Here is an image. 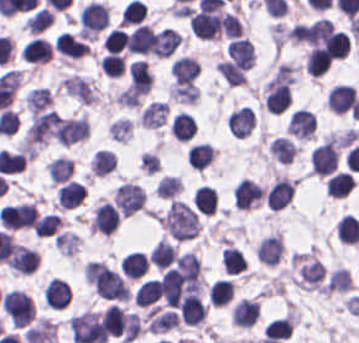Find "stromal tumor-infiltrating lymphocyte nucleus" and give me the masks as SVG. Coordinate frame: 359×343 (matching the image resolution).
I'll list each match as a JSON object with an SVG mask.
<instances>
[{"instance_id":"bc302bb0","label":"stromal tumor-infiltrating lymphocyte nucleus","mask_w":359,"mask_h":343,"mask_svg":"<svg viewBox=\"0 0 359 343\" xmlns=\"http://www.w3.org/2000/svg\"><path fill=\"white\" fill-rule=\"evenodd\" d=\"M339 150L332 139H325L309 153L310 171L320 175L330 173L337 165Z\"/></svg>"},{"instance_id":"52c7bb5b","label":"stromal tumor-infiltrating lymphocyte nucleus","mask_w":359,"mask_h":343,"mask_svg":"<svg viewBox=\"0 0 359 343\" xmlns=\"http://www.w3.org/2000/svg\"><path fill=\"white\" fill-rule=\"evenodd\" d=\"M188 20L194 36L212 39L221 34V19L217 12L195 10L190 13Z\"/></svg>"},{"instance_id":"3290ff9b","label":"stromal tumor-infiltrating lymphocyte nucleus","mask_w":359,"mask_h":343,"mask_svg":"<svg viewBox=\"0 0 359 343\" xmlns=\"http://www.w3.org/2000/svg\"><path fill=\"white\" fill-rule=\"evenodd\" d=\"M264 100L267 111L279 114L291 101L288 83L282 78L272 77L264 88Z\"/></svg>"},{"instance_id":"abfb95fc","label":"stromal tumor-infiltrating lymphocyte nucleus","mask_w":359,"mask_h":343,"mask_svg":"<svg viewBox=\"0 0 359 343\" xmlns=\"http://www.w3.org/2000/svg\"><path fill=\"white\" fill-rule=\"evenodd\" d=\"M107 23V5L90 0L80 9V31L82 33H97Z\"/></svg>"},{"instance_id":"9ea309e8","label":"stromal tumor-infiltrating lymphocyte nucleus","mask_w":359,"mask_h":343,"mask_svg":"<svg viewBox=\"0 0 359 343\" xmlns=\"http://www.w3.org/2000/svg\"><path fill=\"white\" fill-rule=\"evenodd\" d=\"M264 194L263 187L249 177H242L232 191L233 203L237 207L251 208L260 202Z\"/></svg>"},{"instance_id":"f3e2335f","label":"stromal tumor-infiltrating lymphocyte nucleus","mask_w":359,"mask_h":343,"mask_svg":"<svg viewBox=\"0 0 359 343\" xmlns=\"http://www.w3.org/2000/svg\"><path fill=\"white\" fill-rule=\"evenodd\" d=\"M294 188L290 178L277 177L264 191V202L272 209L285 207L293 198Z\"/></svg>"},{"instance_id":"4f13568d","label":"stromal tumor-infiltrating lymphocyte nucleus","mask_w":359,"mask_h":343,"mask_svg":"<svg viewBox=\"0 0 359 343\" xmlns=\"http://www.w3.org/2000/svg\"><path fill=\"white\" fill-rule=\"evenodd\" d=\"M120 213L110 201H103L92 215V229L101 234H111L118 228Z\"/></svg>"},{"instance_id":"2a367800","label":"stromal tumor-infiltrating lymphocyte nucleus","mask_w":359,"mask_h":343,"mask_svg":"<svg viewBox=\"0 0 359 343\" xmlns=\"http://www.w3.org/2000/svg\"><path fill=\"white\" fill-rule=\"evenodd\" d=\"M71 294L67 281L51 276L42 286V301L46 306L62 308L66 306Z\"/></svg>"},{"instance_id":"4803ca6d","label":"stromal tumor-infiltrating lymphocyte nucleus","mask_w":359,"mask_h":343,"mask_svg":"<svg viewBox=\"0 0 359 343\" xmlns=\"http://www.w3.org/2000/svg\"><path fill=\"white\" fill-rule=\"evenodd\" d=\"M355 97L356 91L353 85L338 83L329 89L326 105L336 114H345L350 110Z\"/></svg>"},{"instance_id":"4245b91a","label":"stromal tumor-infiltrating lymphocyte nucleus","mask_w":359,"mask_h":343,"mask_svg":"<svg viewBox=\"0 0 359 343\" xmlns=\"http://www.w3.org/2000/svg\"><path fill=\"white\" fill-rule=\"evenodd\" d=\"M206 313V305L201 296L194 292H186L180 300V320L191 325L200 323Z\"/></svg>"},{"instance_id":"4c9ddf68","label":"stromal tumor-infiltrating lymphocyte nucleus","mask_w":359,"mask_h":343,"mask_svg":"<svg viewBox=\"0 0 359 343\" xmlns=\"http://www.w3.org/2000/svg\"><path fill=\"white\" fill-rule=\"evenodd\" d=\"M38 261L39 253L35 249L15 242L7 258V265L30 274L35 270Z\"/></svg>"},{"instance_id":"2761f720","label":"stromal tumor-infiltrating lymphocyte nucleus","mask_w":359,"mask_h":343,"mask_svg":"<svg viewBox=\"0 0 359 343\" xmlns=\"http://www.w3.org/2000/svg\"><path fill=\"white\" fill-rule=\"evenodd\" d=\"M227 122L235 135H248L256 123L253 108L249 104L238 106L228 115Z\"/></svg>"},{"instance_id":"3c572f05","label":"stromal tumor-infiltrating lymphocyte nucleus","mask_w":359,"mask_h":343,"mask_svg":"<svg viewBox=\"0 0 359 343\" xmlns=\"http://www.w3.org/2000/svg\"><path fill=\"white\" fill-rule=\"evenodd\" d=\"M316 127L313 111L304 108L294 110L288 119L287 130L300 137H313Z\"/></svg>"},{"instance_id":"42bb06b2","label":"stromal tumor-infiltrating lymphocyte nucleus","mask_w":359,"mask_h":343,"mask_svg":"<svg viewBox=\"0 0 359 343\" xmlns=\"http://www.w3.org/2000/svg\"><path fill=\"white\" fill-rule=\"evenodd\" d=\"M129 85L135 94H145L152 83L153 76L146 61L134 59L128 64Z\"/></svg>"},{"instance_id":"9e4306bb","label":"stromal tumor-infiltrating lymphocyte nucleus","mask_w":359,"mask_h":343,"mask_svg":"<svg viewBox=\"0 0 359 343\" xmlns=\"http://www.w3.org/2000/svg\"><path fill=\"white\" fill-rule=\"evenodd\" d=\"M201 264L191 250L180 253L174 263V270L183 281L198 284Z\"/></svg>"},{"instance_id":"04cf8593","label":"stromal tumor-infiltrating lymphocyte nucleus","mask_w":359,"mask_h":343,"mask_svg":"<svg viewBox=\"0 0 359 343\" xmlns=\"http://www.w3.org/2000/svg\"><path fill=\"white\" fill-rule=\"evenodd\" d=\"M321 40L324 49L331 57H345L350 49L349 36L340 28L330 26Z\"/></svg>"},{"instance_id":"e9af9c67","label":"stromal tumor-infiltrating lymphocyte nucleus","mask_w":359,"mask_h":343,"mask_svg":"<svg viewBox=\"0 0 359 343\" xmlns=\"http://www.w3.org/2000/svg\"><path fill=\"white\" fill-rule=\"evenodd\" d=\"M152 40L150 27L139 22L126 36L124 47L128 52L148 54Z\"/></svg>"},{"instance_id":"782c7336","label":"stromal tumor-infiltrating lymphocyte nucleus","mask_w":359,"mask_h":343,"mask_svg":"<svg viewBox=\"0 0 359 343\" xmlns=\"http://www.w3.org/2000/svg\"><path fill=\"white\" fill-rule=\"evenodd\" d=\"M259 316L258 300L242 297L233 306L231 320L238 326H252Z\"/></svg>"},{"instance_id":"cac63f63","label":"stromal tumor-infiltrating lymphocyte nucleus","mask_w":359,"mask_h":343,"mask_svg":"<svg viewBox=\"0 0 359 343\" xmlns=\"http://www.w3.org/2000/svg\"><path fill=\"white\" fill-rule=\"evenodd\" d=\"M54 47L57 52L70 57H80L89 53L88 43L74 36L68 31L57 33Z\"/></svg>"},{"instance_id":"2e467ee5","label":"stromal tumor-infiltrating lymphocyte nucleus","mask_w":359,"mask_h":343,"mask_svg":"<svg viewBox=\"0 0 359 343\" xmlns=\"http://www.w3.org/2000/svg\"><path fill=\"white\" fill-rule=\"evenodd\" d=\"M226 54L242 67H250L254 61L253 47L248 37H235L227 46Z\"/></svg>"},{"instance_id":"7eef579d","label":"stromal tumor-infiltrating lymphocyte nucleus","mask_w":359,"mask_h":343,"mask_svg":"<svg viewBox=\"0 0 359 343\" xmlns=\"http://www.w3.org/2000/svg\"><path fill=\"white\" fill-rule=\"evenodd\" d=\"M200 63L196 57L183 54L176 57L170 65V73L175 80L195 79L199 72Z\"/></svg>"},{"instance_id":"c26a33f6","label":"stromal tumor-infiltrating lymphocyte nucleus","mask_w":359,"mask_h":343,"mask_svg":"<svg viewBox=\"0 0 359 343\" xmlns=\"http://www.w3.org/2000/svg\"><path fill=\"white\" fill-rule=\"evenodd\" d=\"M87 188L81 181L70 179L57 191L60 207L72 208L81 203Z\"/></svg>"},{"instance_id":"3e0999b9","label":"stromal tumor-infiltrating lymphocyte nucleus","mask_w":359,"mask_h":343,"mask_svg":"<svg viewBox=\"0 0 359 343\" xmlns=\"http://www.w3.org/2000/svg\"><path fill=\"white\" fill-rule=\"evenodd\" d=\"M51 46L43 38H30L22 47L20 54L21 58L29 62H40L51 57Z\"/></svg>"},{"instance_id":"a0a3295f","label":"stromal tumor-infiltrating lymphocyte nucleus","mask_w":359,"mask_h":343,"mask_svg":"<svg viewBox=\"0 0 359 343\" xmlns=\"http://www.w3.org/2000/svg\"><path fill=\"white\" fill-rule=\"evenodd\" d=\"M195 122L189 111L179 110L175 113L169 123V131L181 140H188L194 136Z\"/></svg>"},{"instance_id":"b6af03f8","label":"stromal tumor-infiltrating lymphocyte nucleus","mask_w":359,"mask_h":343,"mask_svg":"<svg viewBox=\"0 0 359 343\" xmlns=\"http://www.w3.org/2000/svg\"><path fill=\"white\" fill-rule=\"evenodd\" d=\"M148 267L145 254L139 250H132L119 258V269L124 276L138 277L146 271Z\"/></svg>"},{"instance_id":"6c763739","label":"stromal tumor-infiltrating lymphocyte nucleus","mask_w":359,"mask_h":343,"mask_svg":"<svg viewBox=\"0 0 359 343\" xmlns=\"http://www.w3.org/2000/svg\"><path fill=\"white\" fill-rule=\"evenodd\" d=\"M354 186L351 172L338 170L325 181V192L331 196L344 197Z\"/></svg>"},{"instance_id":"fa64b396","label":"stromal tumor-infiltrating lymphocyte nucleus","mask_w":359,"mask_h":343,"mask_svg":"<svg viewBox=\"0 0 359 343\" xmlns=\"http://www.w3.org/2000/svg\"><path fill=\"white\" fill-rule=\"evenodd\" d=\"M176 251L177 249L174 244L160 238L154 243L148 258L155 267L163 269L174 262Z\"/></svg>"},{"instance_id":"21d57d70","label":"stromal tumor-infiltrating lymphocyte nucleus","mask_w":359,"mask_h":343,"mask_svg":"<svg viewBox=\"0 0 359 343\" xmlns=\"http://www.w3.org/2000/svg\"><path fill=\"white\" fill-rule=\"evenodd\" d=\"M126 314L122 307L108 305L101 318L104 331L115 335L121 334L126 325Z\"/></svg>"},{"instance_id":"02f42fee","label":"stromal tumor-infiltrating lymphocyte nucleus","mask_w":359,"mask_h":343,"mask_svg":"<svg viewBox=\"0 0 359 343\" xmlns=\"http://www.w3.org/2000/svg\"><path fill=\"white\" fill-rule=\"evenodd\" d=\"M160 293L159 279L154 277L144 278L136 287L133 301L139 305H148L156 300Z\"/></svg>"},{"instance_id":"18da8d3c","label":"stromal tumor-infiltrating lymphocyte nucleus","mask_w":359,"mask_h":343,"mask_svg":"<svg viewBox=\"0 0 359 343\" xmlns=\"http://www.w3.org/2000/svg\"><path fill=\"white\" fill-rule=\"evenodd\" d=\"M217 205L215 188L200 184L195 188V208L201 214H212Z\"/></svg>"},{"instance_id":"8379cbfb","label":"stromal tumor-infiltrating lymphocyte nucleus","mask_w":359,"mask_h":343,"mask_svg":"<svg viewBox=\"0 0 359 343\" xmlns=\"http://www.w3.org/2000/svg\"><path fill=\"white\" fill-rule=\"evenodd\" d=\"M269 152L277 160L289 162L296 151L295 144L288 136L276 135L268 146Z\"/></svg>"},{"instance_id":"023d44f5","label":"stromal tumor-infiltrating lymphocyte nucleus","mask_w":359,"mask_h":343,"mask_svg":"<svg viewBox=\"0 0 359 343\" xmlns=\"http://www.w3.org/2000/svg\"><path fill=\"white\" fill-rule=\"evenodd\" d=\"M117 159L110 149H97L91 159L90 168L95 176H105L112 171Z\"/></svg>"},{"instance_id":"afbf053c","label":"stromal tumor-infiltrating lymphocyte nucleus","mask_w":359,"mask_h":343,"mask_svg":"<svg viewBox=\"0 0 359 343\" xmlns=\"http://www.w3.org/2000/svg\"><path fill=\"white\" fill-rule=\"evenodd\" d=\"M216 69L225 82L230 85L241 84L246 78V68L225 58L220 59Z\"/></svg>"},{"instance_id":"1d375fb5","label":"stromal tumor-infiltrating lymphocyte nucleus","mask_w":359,"mask_h":343,"mask_svg":"<svg viewBox=\"0 0 359 343\" xmlns=\"http://www.w3.org/2000/svg\"><path fill=\"white\" fill-rule=\"evenodd\" d=\"M221 262L226 272H239L247 267V260L241 248L225 245Z\"/></svg>"},{"instance_id":"84afeb40","label":"stromal tumor-infiltrating lymphocyte nucleus","mask_w":359,"mask_h":343,"mask_svg":"<svg viewBox=\"0 0 359 343\" xmlns=\"http://www.w3.org/2000/svg\"><path fill=\"white\" fill-rule=\"evenodd\" d=\"M234 290L233 281L226 278L216 279L209 288V298L215 305L231 301Z\"/></svg>"},{"instance_id":"a6e9041d","label":"stromal tumor-infiltrating lymphocyte nucleus","mask_w":359,"mask_h":343,"mask_svg":"<svg viewBox=\"0 0 359 343\" xmlns=\"http://www.w3.org/2000/svg\"><path fill=\"white\" fill-rule=\"evenodd\" d=\"M338 237L344 243H357L359 240L358 219L345 213L338 221Z\"/></svg>"},{"instance_id":"83f04bf1","label":"stromal tumor-infiltrating lymphocyte nucleus","mask_w":359,"mask_h":343,"mask_svg":"<svg viewBox=\"0 0 359 343\" xmlns=\"http://www.w3.org/2000/svg\"><path fill=\"white\" fill-rule=\"evenodd\" d=\"M330 60L331 58L327 52L315 44L305 58L309 74H322L326 70Z\"/></svg>"},{"instance_id":"16295066","label":"stromal tumor-infiltrating lymphocyte nucleus","mask_w":359,"mask_h":343,"mask_svg":"<svg viewBox=\"0 0 359 343\" xmlns=\"http://www.w3.org/2000/svg\"><path fill=\"white\" fill-rule=\"evenodd\" d=\"M291 319L288 316L274 317L265 323L263 335L266 338L285 339L289 334Z\"/></svg>"},{"instance_id":"a33fdf23","label":"stromal tumor-infiltrating lymphocyte nucleus","mask_w":359,"mask_h":343,"mask_svg":"<svg viewBox=\"0 0 359 343\" xmlns=\"http://www.w3.org/2000/svg\"><path fill=\"white\" fill-rule=\"evenodd\" d=\"M213 154V146L208 142H195L188 152V162L197 168L207 166Z\"/></svg>"},{"instance_id":"c8d0df70","label":"stromal tumor-infiltrating lymphocyte nucleus","mask_w":359,"mask_h":343,"mask_svg":"<svg viewBox=\"0 0 359 343\" xmlns=\"http://www.w3.org/2000/svg\"><path fill=\"white\" fill-rule=\"evenodd\" d=\"M52 21V12L39 7L24 18L23 27L31 32H39Z\"/></svg>"},{"instance_id":"7b516f1d","label":"stromal tumor-infiltrating lymphocyte nucleus","mask_w":359,"mask_h":343,"mask_svg":"<svg viewBox=\"0 0 359 343\" xmlns=\"http://www.w3.org/2000/svg\"><path fill=\"white\" fill-rule=\"evenodd\" d=\"M46 169L52 181H66L72 174V161L65 156H57L46 165Z\"/></svg>"},{"instance_id":"ccc9de39","label":"stromal tumor-infiltrating lymphocyte nucleus","mask_w":359,"mask_h":343,"mask_svg":"<svg viewBox=\"0 0 359 343\" xmlns=\"http://www.w3.org/2000/svg\"><path fill=\"white\" fill-rule=\"evenodd\" d=\"M61 225L60 217L53 212H46L33 223L35 236H48L53 234Z\"/></svg>"},{"instance_id":"50b3126c","label":"stromal tumor-infiltrating lymphocyte nucleus","mask_w":359,"mask_h":343,"mask_svg":"<svg viewBox=\"0 0 359 343\" xmlns=\"http://www.w3.org/2000/svg\"><path fill=\"white\" fill-rule=\"evenodd\" d=\"M181 187L180 175L164 173L155 190L160 197H174Z\"/></svg>"},{"instance_id":"6da75f8f","label":"stromal tumor-infiltrating lymphocyte nucleus","mask_w":359,"mask_h":343,"mask_svg":"<svg viewBox=\"0 0 359 343\" xmlns=\"http://www.w3.org/2000/svg\"><path fill=\"white\" fill-rule=\"evenodd\" d=\"M127 34L128 32L122 27L114 26L103 36V47L117 53L123 47Z\"/></svg>"},{"instance_id":"fc20714e","label":"stromal tumor-infiltrating lymphocyte nucleus","mask_w":359,"mask_h":343,"mask_svg":"<svg viewBox=\"0 0 359 343\" xmlns=\"http://www.w3.org/2000/svg\"><path fill=\"white\" fill-rule=\"evenodd\" d=\"M132 124L127 116H119L107 125L109 133L118 140H126L131 132Z\"/></svg>"},{"instance_id":"894b7857","label":"stromal tumor-infiltrating lymphocyte nucleus","mask_w":359,"mask_h":343,"mask_svg":"<svg viewBox=\"0 0 359 343\" xmlns=\"http://www.w3.org/2000/svg\"><path fill=\"white\" fill-rule=\"evenodd\" d=\"M221 27L227 36L239 37L243 32L241 20L232 11L222 13Z\"/></svg>"},{"instance_id":"fb6c686a","label":"stromal tumor-infiltrating lymphocyte nucleus","mask_w":359,"mask_h":343,"mask_svg":"<svg viewBox=\"0 0 359 343\" xmlns=\"http://www.w3.org/2000/svg\"><path fill=\"white\" fill-rule=\"evenodd\" d=\"M98 62L101 68L109 75H119L123 70L124 60L122 54L108 52Z\"/></svg>"}]
</instances>
